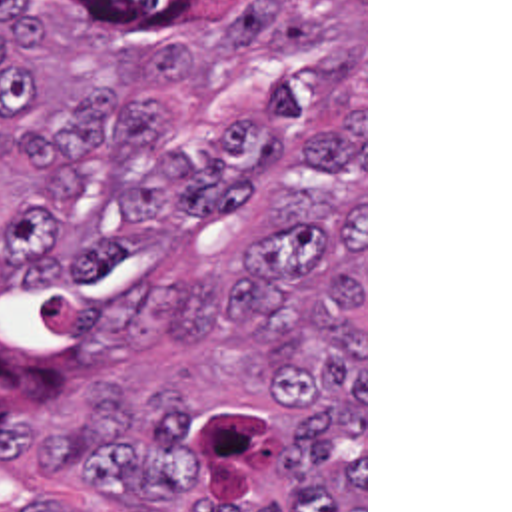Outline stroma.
I'll list each match as a JSON object with an SVG mask.
<instances>
[{"mask_svg":"<svg viewBox=\"0 0 512 512\" xmlns=\"http://www.w3.org/2000/svg\"><path fill=\"white\" fill-rule=\"evenodd\" d=\"M33 42L13 48L39 68V118L19 140L1 142L0 180V512L31 495L61 512L98 509L94 491L23 473L33 431L69 415L76 395L98 385L126 395H184L192 451L218 509L278 507L284 485L272 453L290 425L286 382L268 350L234 330L220 348L168 360V330L190 282L232 266L254 248L270 198L294 174L304 146L294 134L246 116L162 108L170 142L186 148L206 134L250 124L280 148V180L250 212L186 232H120L124 258L63 286H11L3 248L5 216L35 186L19 166L29 134H59L63 120L94 94H120L88 60L92 14L61 0H29ZM364 512H368V0H364Z\"/></svg>","mask_w":512,"mask_h":512,"instance_id":"1","label":"stroma"}]
</instances>
